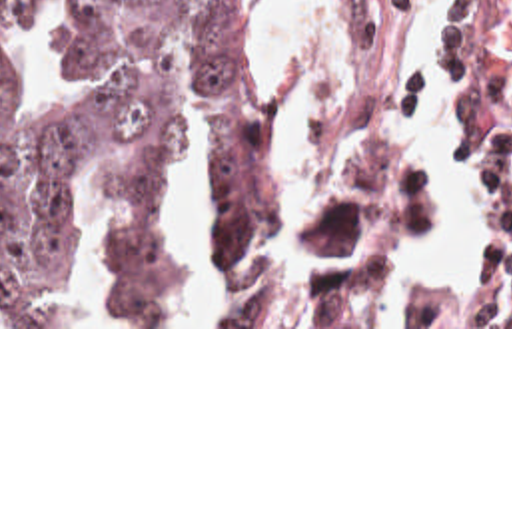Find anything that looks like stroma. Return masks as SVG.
I'll return each mask as SVG.
<instances>
[{"label": "stroma", "instance_id": "35a3bbf8", "mask_svg": "<svg viewBox=\"0 0 512 512\" xmlns=\"http://www.w3.org/2000/svg\"><path fill=\"white\" fill-rule=\"evenodd\" d=\"M307 46L303 0H289ZM355 40V87L345 123H319L299 115L303 79L293 107V127L303 143L349 133H403L389 119L413 131V26L405 10H385L375 0H345ZM451 89L459 101L473 141L475 167L495 137L512 123V0H463L451 46ZM389 119H385L383 115ZM409 173L395 219V251L439 211V185L417 155L415 135ZM162 185H136L140 197ZM389 277V273H387ZM387 281V279H385ZM385 285V283H383ZM381 295V293H379ZM379 301V297H377ZM447 301L409 313L407 327H387L375 307L365 325L303 327H168V325H0V329H512V327H439Z\"/></svg>", "mask_w": 512, "mask_h": 512}]
</instances>
